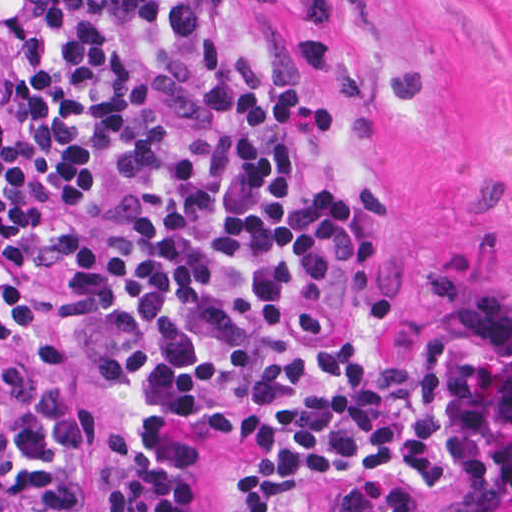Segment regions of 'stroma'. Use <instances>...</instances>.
I'll return each mask as SVG.
<instances>
[{
	"mask_svg": "<svg viewBox=\"0 0 512 512\" xmlns=\"http://www.w3.org/2000/svg\"><path fill=\"white\" fill-rule=\"evenodd\" d=\"M265 110L252 135L305 168L341 214L344 257L374 351H406L460 289L512 290V0H267ZM49 364L0 359V425L47 394L94 429L83 512H114L109 475L125 393L79 343L71 269L34 282ZM194 512H238L252 443L187 423ZM349 485L301 483L276 512H339Z\"/></svg>",
	"mask_w": 512,
	"mask_h": 512,
	"instance_id": "35a3bbf8",
	"label": "stroma"
}]
</instances>
